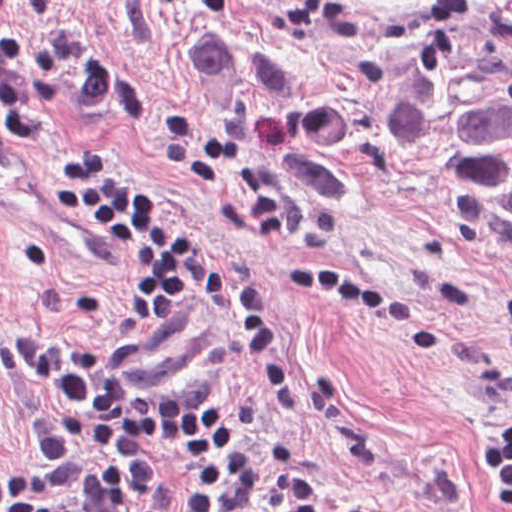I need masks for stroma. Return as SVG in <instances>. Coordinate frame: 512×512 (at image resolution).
<instances>
[{"label": "stroma", "mask_w": 512, "mask_h": 512, "mask_svg": "<svg viewBox=\"0 0 512 512\" xmlns=\"http://www.w3.org/2000/svg\"><path fill=\"white\" fill-rule=\"evenodd\" d=\"M482 0H13L0 37L42 42L104 68V100L27 97L57 142L116 152L176 211L203 257L255 278L275 311L291 374L277 412L245 347L244 322L190 288L159 329L134 323L148 266L89 222L50 209L49 162L0 122V477L33 468L32 423L52 408L12 335L99 342L133 387H214L244 424L228 449L173 448L167 471L127 503L149 512L177 485L266 443L302 448L306 474L379 512H497L482 455L512 415V366L492 323L512 287V252L449 215L396 163L386 139L414 56ZM243 150L248 180H271L288 232L258 231L218 180L155 144L163 112ZM299 264L403 291L439 330L433 353L322 287Z\"/></svg>", "instance_id": "obj_1"}]
</instances>
